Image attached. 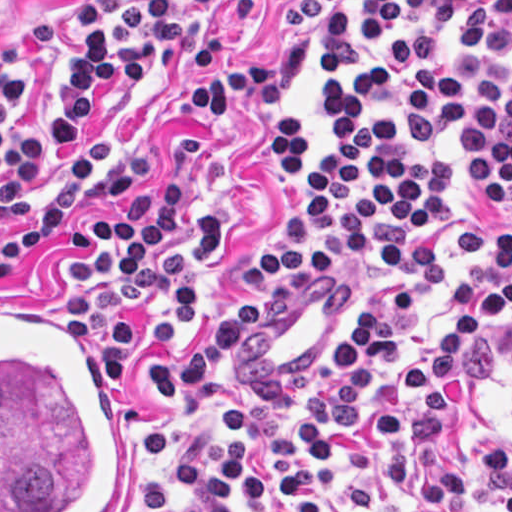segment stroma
<instances>
[{
    "mask_svg": "<svg viewBox=\"0 0 512 512\" xmlns=\"http://www.w3.org/2000/svg\"><path fill=\"white\" fill-rule=\"evenodd\" d=\"M281 0H250L222 13H205L184 1L186 43L155 68L147 53L144 80L108 100L94 128L72 152L41 169L26 187L21 204L0 216V250L56 196L65 176L85 154L107 175L131 171L155 186L165 174L191 175L192 193L168 244L192 237L195 208L216 212L222 250L191 281L184 331L174 347L146 339V323L163 318V303L115 314L133 326V353L124 365L121 389H112L131 435L129 512H187L204 500L179 490L180 462L207 456L219 432L217 414L196 392L159 407L152 399L149 359L175 354L181 360L211 323L245 297H262V316L222 368L220 378L251 409L243 440L251 463L282 475L297 468L299 426L310 411V390L346 330L365 308H377L398 288L412 296L410 320L401 324L403 348L385 365L366 393L363 410L401 413L406 427L422 401L410 390L406 368L425 356L440 327L452 326L456 276L493 269V237L478 230L464 206L461 134L449 129L437 148L452 166L450 218L443 230L409 228L441 246L443 271L417 278L388 277L362 259L342 255L320 268L293 275L252 278L242 267L270 238L285 198L305 176L280 177L274 149L278 118L289 113L307 149L326 144L317 120V101L327 81L323 56L312 58L299 81L275 102L250 91L235 110H195L184 89L208 83L211 74L269 65L283 46L301 38L298 27L274 20ZM76 33V0H0V68L12 63L23 76L25 116L36 122L43 96L55 85ZM512 69V56L480 54ZM512 223V212L481 204ZM132 204H105L98 191L85 194L67 215L64 237L25 259L0 282V301L41 299L69 315L76 294L111 282L75 277L71 261L98 257L105 246L92 237L101 218H121ZM456 327H452L450 335ZM99 362L103 343H89ZM439 398L447 402L434 439L446 469H466L478 443L512 450V314L500 317L472 344L457 378H439ZM389 439L374 438L363 423L353 424L335 459V475L323 512H400L412 490L386 488L382 456ZM228 512H286V500L272 494L254 506H240L229 491ZM423 512H505L485 476L467 479L465 493Z\"/></svg>",
    "mask_w": 512,
    "mask_h": 512,
    "instance_id": "stroma-1",
    "label": "stroma"
}]
</instances>
